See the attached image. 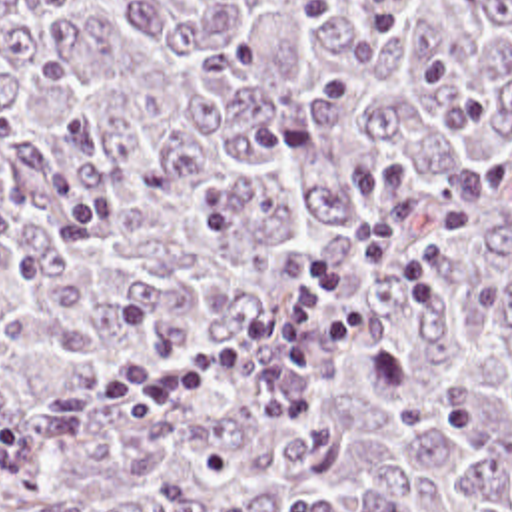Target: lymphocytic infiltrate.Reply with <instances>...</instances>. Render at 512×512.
<instances>
[{"label": "lymphocytic infiltrate", "instance_id": "f902f5d3", "mask_svg": "<svg viewBox=\"0 0 512 512\" xmlns=\"http://www.w3.org/2000/svg\"><path fill=\"white\" fill-rule=\"evenodd\" d=\"M350 8L378 36H400L406 0H312L306 16L320 20ZM474 218L472 202L446 204L424 246L414 248L406 218L394 216L362 238L364 268L350 270L330 256L306 260L292 294L229 334H197L183 320L167 318L141 302L119 308L121 324L151 346L155 356L127 354L111 364L97 388L115 422H137L157 406L213 384L207 366L185 352L215 358L223 376L248 362L246 400L252 412L276 420L306 414L320 372L312 344V316L320 304L340 306L318 334L320 352L332 360L354 346L370 326L368 298L382 274L398 276L402 304L422 318L440 308V264L448 242Z\"/></svg>", "mask_w": 512, "mask_h": 512}]
</instances>
